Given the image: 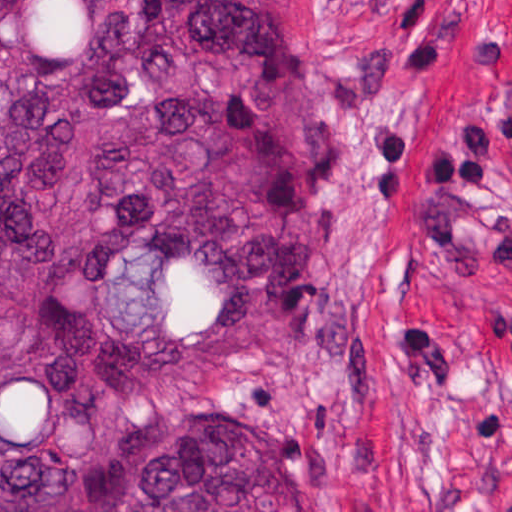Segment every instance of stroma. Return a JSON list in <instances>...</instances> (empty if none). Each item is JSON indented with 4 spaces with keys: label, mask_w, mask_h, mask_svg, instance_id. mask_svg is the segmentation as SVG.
Segmentation results:
<instances>
[{
    "label": "stroma",
    "mask_w": 512,
    "mask_h": 512,
    "mask_svg": "<svg viewBox=\"0 0 512 512\" xmlns=\"http://www.w3.org/2000/svg\"><path fill=\"white\" fill-rule=\"evenodd\" d=\"M308 269L250 369L302 512L512 500V0H303Z\"/></svg>",
    "instance_id": "1"
}]
</instances>
